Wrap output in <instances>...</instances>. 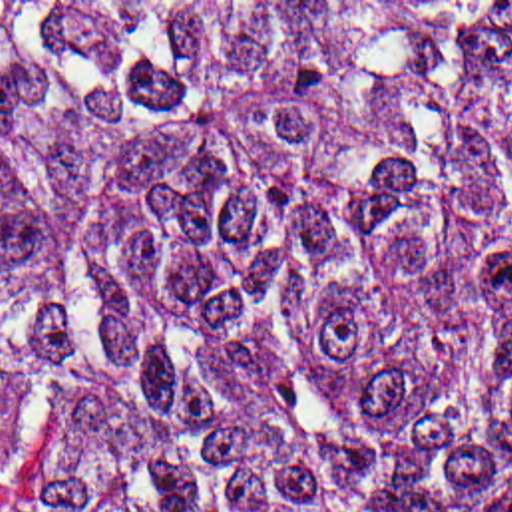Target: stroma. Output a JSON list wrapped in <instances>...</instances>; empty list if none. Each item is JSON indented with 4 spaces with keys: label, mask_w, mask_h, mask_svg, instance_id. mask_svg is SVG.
Returning a JSON list of instances; mask_svg holds the SVG:
<instances>
[{
    "label": "stroma",
    "mask_w": 512,
    "mask_h": 512,
    "mask_svg": "<svg viewBox=\"0 0 512 512\" xmlns=\"http://www.w3.org/2000/svg\"><path fill=\"white\" fill-rule=\"evenodd\" d=\"M0 2H512V0H0ZM509 498H512V486L503 496V500L497 504V508H501Z\"/></svg>",
    "instance_id": "1"
}]
</instances>
